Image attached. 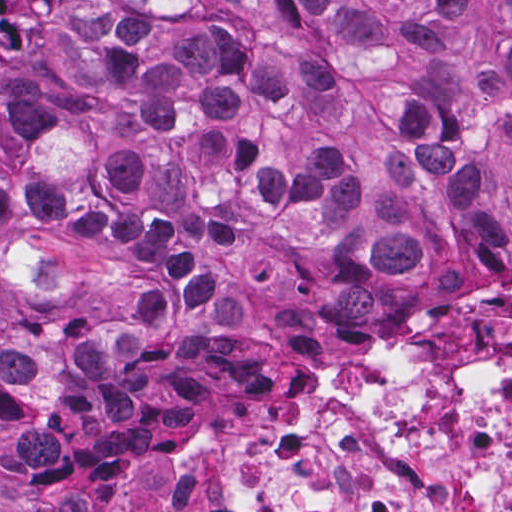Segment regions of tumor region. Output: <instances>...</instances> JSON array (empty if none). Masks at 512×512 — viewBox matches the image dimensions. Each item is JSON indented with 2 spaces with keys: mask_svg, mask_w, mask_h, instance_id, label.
Segmentation results:
<instances>
[{
  "mask_svg": "<svg viewBox=\"0 0 512 512\" xmlns=\"http://www.w3.org/2000/svg\"><path fill=\"white\" fill-rule=\"evenodd\" d=\"M0 512H92L294 322L512 272V0H0Z\"/></svg>",
  "mask_w": 512,
  "mask_h": 512,
  "instance_id": "1",
  "label": "tumor region"
}]
</instances>
